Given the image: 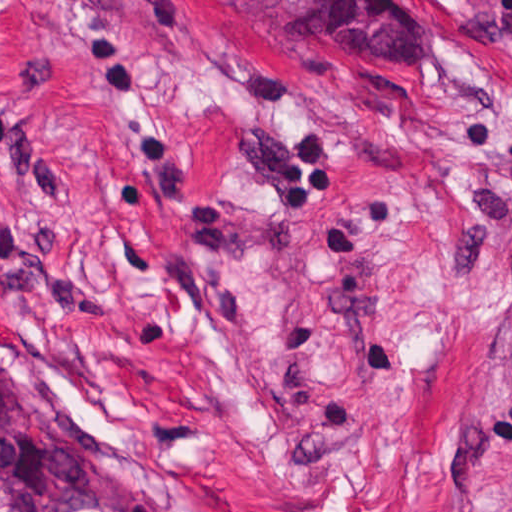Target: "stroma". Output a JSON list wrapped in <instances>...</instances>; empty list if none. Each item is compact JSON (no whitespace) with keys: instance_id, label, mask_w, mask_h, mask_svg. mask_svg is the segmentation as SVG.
<instances>
[{"instance_id":"1","label":"stroma","mask_w":512,"mask_h":512,"mask_svg":"<svg viewBox=\"0 0 512 512\" xmlns=\"http://www.w3.org/2000/svg\"><path fill=\"white\" fill-rule=\"evenodd\" d=\"M0 367L178 512H512V0H0Z\"/></svg>"}]
</instances>
